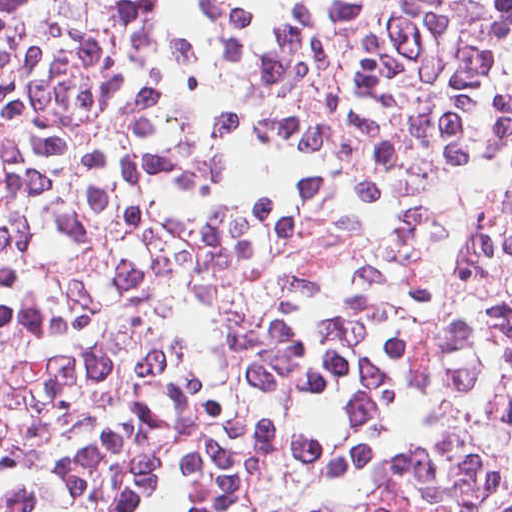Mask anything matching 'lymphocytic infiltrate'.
<instances>
[{"instance_id":"1","label":"lymphocytic infiltrate","mask_w":512,"mask_h":512,"mask_svg":"<svg viewBox=\"0 0 512 512\" xmlns=\"http://www.w3.org/2000/svg\"><path fill=\"white\" fill-rule=\"evenodd\" d=\"M0 512H512V0H0Z\"/></svg>"}]
</instances>
